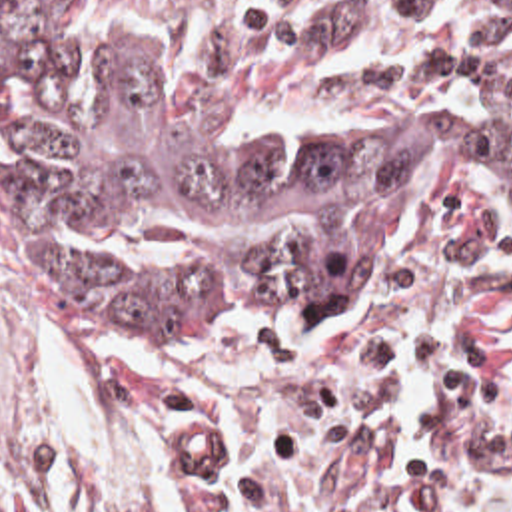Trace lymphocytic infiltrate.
I'll return each mask as SVG.
<instances>
[{"label": "lymphocytic infiltrate", "mask_w": 512, "mask_h": 512, "mask_svg": "<svg viewBox=\"0 0 512 512\" xmlns=\"http://www.w3.org/2000/svg\"><path fill=\"white\" fill-rule=\"evenodd\" d=\"M313 75L339 89L512 115V23L455 15L367 35L321 55Z\"/></svg>", "instance_id": "1"}]
</instances>
